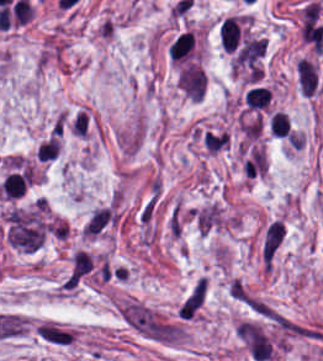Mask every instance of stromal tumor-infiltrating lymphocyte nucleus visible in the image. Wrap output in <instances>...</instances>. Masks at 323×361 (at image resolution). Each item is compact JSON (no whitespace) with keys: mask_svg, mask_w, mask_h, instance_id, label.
<instances>
[{"mask_svg":"<svg viewBox=\"0 0 323 361\" xmlns=\"http://www.w3.org/2000/svg\"><path fill=\"white\" fill-rule=\"evenodd\" d=\"M113 225L112 209L106 206H100L92 209L81 230L80 236L88 239H94L100 236L104 231Z\"/></svg>","mask_w":323,"mask_h":361,"instance_id":"bc302bb0","label":"stromal tumor-infiltrating lymphocyte nucleus"},{"mask_svg":"<svg viewBox=\"0 0 323 361\" xmlns=\"http://www.w3.org/2000/svg\"><path fill=\"white\" fill-rule=\"evenodd\" d=\"M29 182L27 169L8 173L0 185L2 198L14 199L18 196Z\"/></svg>","mask_w":323,"mask_h":361,"instance_id":"52c7bb5b","label":"stromal tumor-infiltrating lymphocyte nucleus"},{"mask_svg":"<svg viewBox=\"0 0 323 361\" xmlns=\"http://www.w3.org/2000/svg\"><path fill=\"white\" fill-rule=\"evenodd\" d=\"M219 39L224 51H233L239 40L240 28L235 16H228L218 28Z\"/></svg>","mask_w":323,"mask_h":361,"instance_id":"3290ff9b","label":"stromal tumor-infiltrating lymphocyte nucleus"},{"mask_svg":"<svg viewBox=\"0 0 323 361\" xmlns=\"http://www.w3.org/2000/svg\"><path fill=\"white\" fill-rule=\"evenodd\" d=\"M269 128L275 137H286L290 132V120L282 110H275Z\"/></svg>","mask_w":323,"mask_h":361,"instance_id":"abfb95fc","label":"stromal tumor-infiltrating lymphocyte nucleus"},{"mask_svg":"<svg viewBox=\"0 0 323 361\" xmlns=\"http://www.w3.org/2000/svg\"><path fill=\"white\" fill-rule=\"evenodd\" d=\"M268 98V91L265 87H252L245 93V100L250 108H264Z\"/></svg>","mask_w":323,"mask_h":361,"instance_id":"9ea309e8","label":"stromal tumor-infiltrating lymphocyte nucleus"}]
</instances>
